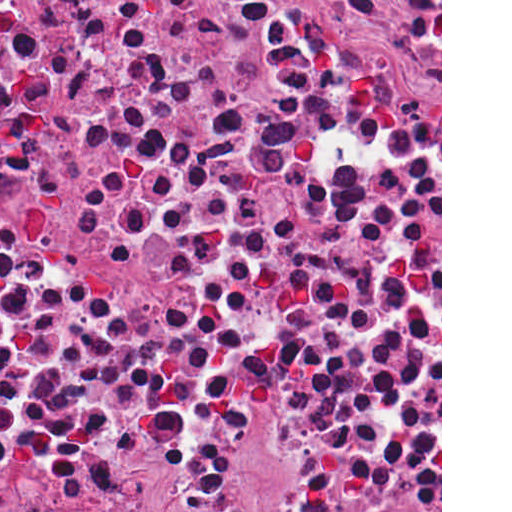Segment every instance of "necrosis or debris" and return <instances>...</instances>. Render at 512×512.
<instances>
[{
    "label": "necrosis or debris",
    "instance_id": "necrosis-or-debris-1",
    "mask_svg": "<svg viewBox=\"0 0 512 512\" xmlns=\"http://www.w3.org/2000/svg\"><path fill=\"white\" fill-rule=\"evenodd\" d=\"M173 0H0V77Z\"/></svg>",
    "mask_w": 512,
    "mask_h": 512
}]
</instances>
